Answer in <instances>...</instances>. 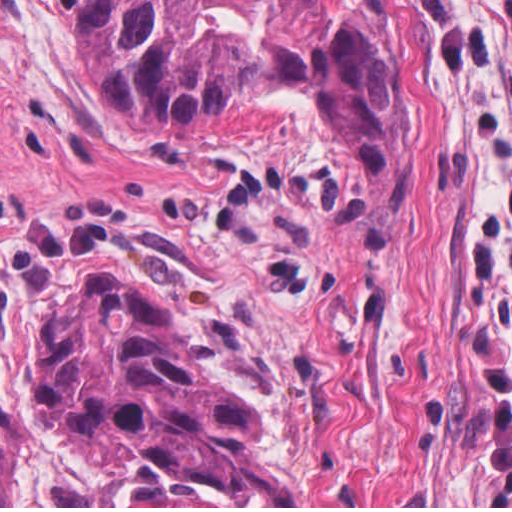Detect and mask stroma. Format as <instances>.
I'll return each instance as SVG.
<instances>
[{
  "instance_id": "35a3bbf8",
  "label": "stroma",
  "mask_w": 512,
  "mask_h": 512,
  "mask_svg": "<svg viewBox=\"0 0 512 512\" xmlns=\"http://www.w3.org/2000/svg\"><path fill=\"white\" fill-rule=\"evenodd\" d=\"M512 204V0H394Z\"/></svg>"
}]
</instances>
